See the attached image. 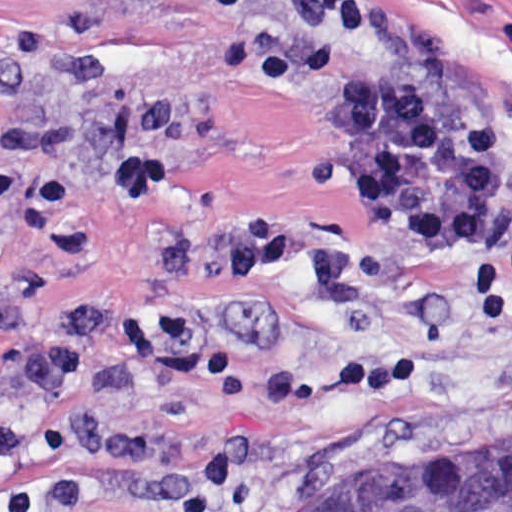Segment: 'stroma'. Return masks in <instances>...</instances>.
Here are the masks:
<instances>
[{
    "label": "stroma",
    "instance_id": "1",
    "mask_svg": "<svg viewBox=\"0 0 512 512\" xmlns=\"http://www.w3.org/2000/svg\"><path fill=\"white\" fill-rule=\"evenodd\" d=\"M288 0H0V302L50 337L109 310L82 375L31 399L0 332V512H287L376 471H454L512 455V0H335L309 40L377 76L490 116L511 180L483 247L417 252L335 188L303 90L259 88ZM176 104L173 174L145 204L110 177L141 139L140 101ZM246 215L364 241L369 300L326 294L308 260L225 288L153 255ZM421 340L386 390L271 403L286 367Z\"/></svg>",
    "mask_w": 512,
    "mask_h": 512
}]
</instances>
